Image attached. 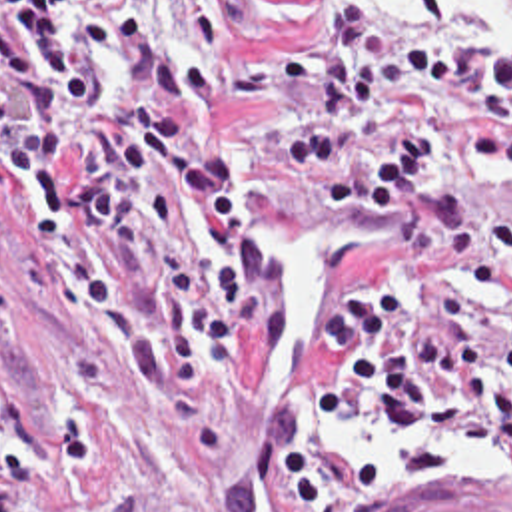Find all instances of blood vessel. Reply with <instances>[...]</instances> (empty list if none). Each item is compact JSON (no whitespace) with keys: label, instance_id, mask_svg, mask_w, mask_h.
Segmentation results:
<instances>
[{"label":"blood vessel","instance_id":"1","mask_svg":"<svg viewBox=\"0 0 512 512\" xmlns=\"http://www.w3.org/2000/svg\"><path fill=\"white\" fill-rule=\"evenodd\" d=\"M503 496L512 498L509 492H483L471 488H459L441 492L429 500L404 508L402 512H512Z\"/></svg>","mask_w":512,"mask_h":512}]
</instances>
